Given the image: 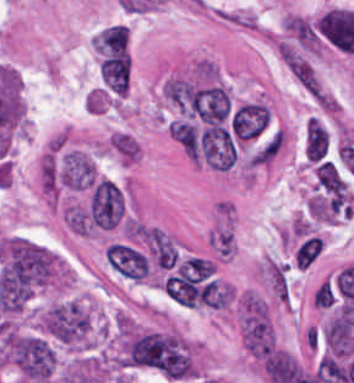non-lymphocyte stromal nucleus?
Wrapping results in <instances>:
<instances>
[{
  "label": "non-lymphocyte stromal nucleus",
  "instance_id": "obj_1",
  "mask_svg": "<svg viewBox=\"0 0 354 383\" xmlns=\"http://www.w3.org/2000/svg\"><path fill=\"white\" fill-rule=\"evenodd\" d=\"M205 240L216 259H233L237 254V235L231 212L215 215Z\"/></svg>",
  "mask_w": 354,
  "mask_h": 383
}]
</instances>
